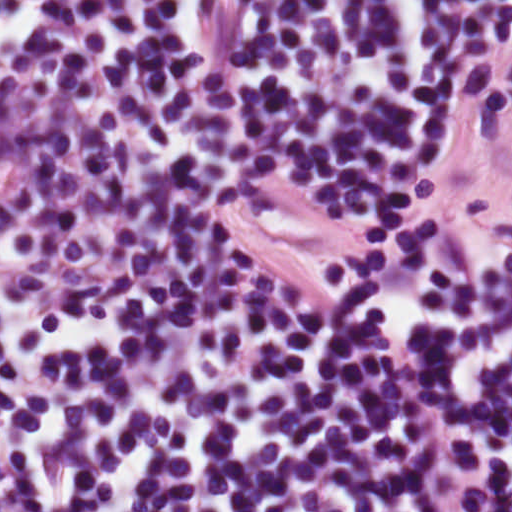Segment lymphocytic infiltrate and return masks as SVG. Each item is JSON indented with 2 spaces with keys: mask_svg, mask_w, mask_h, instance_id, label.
Here are the masks:
<instances>
[{
  "mask_svg": "<svg viewBox=\"0 0 512 512\" xmlns=\"http://www.w3.org/2000/svg\"><path fill=\"white\" fill-rule=\"evenodd\" d=\"M447 101L402 0H0V512H512V247L367 262Z\"/></svg>",
  "mask_w": 512,
  "mask_h": 512,
  "instance_id": "1",
  "label": "lymphocytic infiltrate"
}]
</instances>
